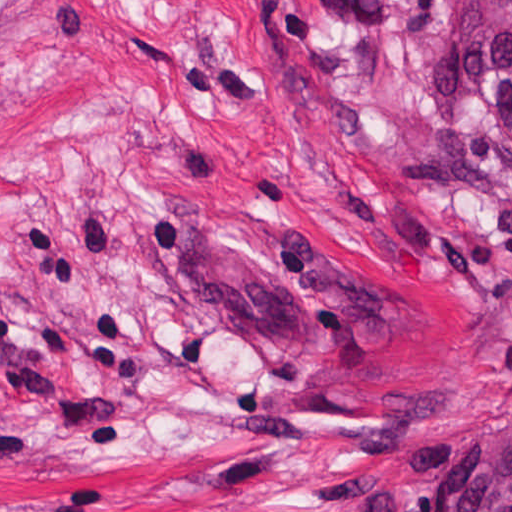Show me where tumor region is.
I'll return each instance as SVG.
<instances>
[{
	"label": "tumor region",
	"instance_id": "tumor-region-1",
	"mask_svg": "<svg viewBox=\"0 0 512 512\" xmlns=\"http://www.w3.org/2000/svg\"><path fill=\"white\" fill-rule=\"evenodd\" d=\"M425 119L453 130L512 194V0H452L420 77ZM439 512H512V427L477 433Z\"/></svg>",
	"mask_w": 512,
	"mask_h": 512
}]
</instances>
